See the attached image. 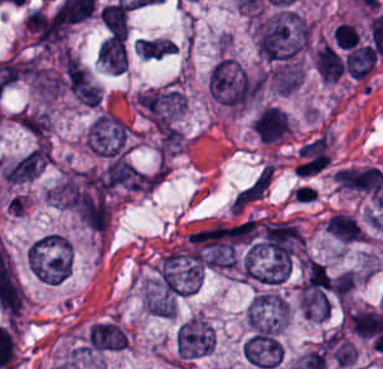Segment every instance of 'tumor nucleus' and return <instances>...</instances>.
Returning a JSON list of instances; mask_svg holds the SVG:
<instances>
[{
  "instance_id": "17",
  "label": "tumor nucleus",
  "mask_w": 383,
  "mask_h": 369,
  "mask_svg": "<svg viewBox=\"0 0 383 369\" xmlns=\"http://www.w3.org/2000/svg\"><path fill=\"white\" fill-rule=\"evenodd\" d=\"M334 39L340 48L351 49L359 44L360 33L349 21H342L334 29Z\"/></svg>"
},
{
  "instance_id": "13",
  "label": "tumor nucleus",
  "mask_w": 383,
  "mask_h": 369,
  "mask_svg": "<svg viewBox=\"0 0 383 369\" xmlns=\"http://www.w3.org/2000/svg\"><path fill=\"white\" fill-rule=\"evenodd\" d=\"M315 64L323 81L335 82L345 71L343 57L332 45L325 42L317 54Z\"/></svg>"
},
{
  "instance_id": "9",
  "label": "tumor nucleus",
  "mask_w": 383,
  "mask_h": 369,
  "mask_svg": "<svg viewBox=\"0 0 383 369\" xmlns=\"http://www.w3.org/2000/svg\"><path fill=\"white\" fill-rule=\"evenodd\" d=\"M289 318L288 304L276 292L258 290L248 307L251 325H284Z\"/></svg>"
},
{
  "instance_id": "3",
  "label": "tumor nucleus",
  "mask_w": 383,
  "mask_h": 369,
  "mask_svg": "<svg viewBox=\"0 0 383 369\" xmlns=\"http://www.w3.org/2000/svg\"><path fill=\"white\" fill-rule=\"evenodd\" d=\"M27 262L33 276L42 283L61 284L71 272L70 244L61 236L46 234L31 244Z\"/></svg>"
},
{
  "instance_id": "4",
  "label": "tumor nucleus",
  "mask_w": 383,
  "mask_h": 369,
  "mask_svg": "<svg viewBox=\"0 0 383 369\" xmlns=\"http://www.w3.org/2000/svg\"><path fill=\"white\" fill-rule=\"evenodd\" d=\"M85 140L89 149L103 158L124 159L128 153V126L118 116L105 111L91 123Z\"/></svg>"
},
{
  "instance_id": "16",
  "label": "tumor nucleus",
  "mask_w": 383,
  "mask_h": 369,
  "mask_svg": "<svg viewBox=\"0 0 383 369\" xmlns=\"http://www.w3.org/2000/svg\"><path fill=\"white\" fill-rule=\"evenodd\" d=\"M328 348L339 367H346L355 362L356 350L341 333H334L328 338Z\"/></svg>"
},
{
  "instance_id": "10",
  "label": "tumor nucleus",
  "mask_w": 383,
  "mask_h": 369,
  "mask_svg": "<svg viewBox=\"0 0 383 369\" xmlns=\"http://www.w3.org/2000/svg\"><path fill=\"white\" fill-rule=\"evenodd\" d=\"M83 347L89 352H115L128 347V337L117 321L102 319L90 325Z\"/></svg>"
},
{
  "instance_id": "8",
  "label": "tumor nucleus",
  "mask_w": 383,
  "mask_h": 369,
  "mask_svg": "<svg viewBox=\"0 0 383 369\" xmlns=\"http://www.w3.org/2000/svg\"><path fill=\"white\" fill-rule=\"evenodd\" d=\"M336 184L352 193L373 198L383 191V173L378 165H345L336 170Z\"/></svg>"
},
{
  "instance_id": "2",
  "label": "tumor nucleus",
  "mask_w": 383,
  "mask_h": 369,
  "mask_svg": "<svg viewBox=\"0 0 383 369\" xmlns=\"http://www.w3.org/2000/svg\"><path fill=\"white\" fill-rule=\"evenodd\" d=\"M212 101L229 110H243L258 98L259 77L235 59L222 57L208 76Z\"/></svg>"
},
{
  "instance_id": "11",
  "label": "tumor nucleus",
  "mask_w": 383,
  "mask_h": 369,
  "mask_svg": "<svg viewBox=\"0 0 383 369\" xmlns=\"http://www.w3.org/2000/svg\"><path fill=\"white\" fill-rule=\"evenodd\" d=\"M256 132L263 142L283 139L291 130L287 112L278 105H265L254 117Z\"/></svg>"
},
{
  "instance_id": "1",
  "label": "tumor nucleus",
  "mask_w": 383,
  "mask_h": 369,
  "mask_svg": "<svg viewBox=\"0 0 383 369\" xmlns=\"http://www.w3.org/2000/svg\"><path fill=\"white\" fill-rule=\"evenodd\" d=\"M310 29L291 9H277L259 15L254 24L258 54L272 63H292L306 48Z\"/></svg>"
},
{
  "instance_id": "6",
  "label": "tumor nucleus",
  "mask_w": 383,
  "mask_h": 369,
  "mask_svg": "<svg viewBox=\"0 0 383 369\" xmlns=\"http://www.w3.org/2000/svg\"><path fill=\"white\" fill-rule=\"evenodd\" d=\"M284 350L279 332L256 330L242 345V356L257 369H271L283 360Z\"/></svg>"
},
{
  "instance_id": "14",
  "label": "tumor nucleus",
  "mask_w": 383,
  "mask_h": 369,
  "mask_svg": "<svg viewBox=\"0 0 383 369\" xmlns=\"http://www.w3.org/2000/svg\"><path fill=\"white\" fill-rule=\"evenodd\" d=\"M378 56L373 45L362 44L347 53L345 70L353 76L365 77L377 63Z\"/></svg>"
},
{
  "instance_id": "7",
  "label": "tumor nucleus",
  "mask_w": 383,
  "mask_h": 369,
  "mask_svg": "<svg viewBox=\"0 0 383 369\" xmlns=\"http://www.w3.org/2000/svg\"><path fill=\"white\" fill-rule=\"evenodd\" d=\"M215 348V334L201 318L180 324L176 334L177 357L195 359L210 355Z\"/></svg>"
},
{
  "instance_id": "15",
  "label": "tumor nucleus",
  "mask_w": 383,
  "mask_h": 369,
  "mask_svg": "<svg viewBox=\"0 0 383 369\" xmlns=\"http://www.w3.org/2000/svg\"><path fill=\"white\" fill-rule=\"evenodd\" d=\"M136 49L142 57L158 59L176 52L177 47L170 38H137Z\"/></svg>"
},
{
  "instance_id": "12",
  "label": "tumor nucleus",
  "mask_w": 383,
  "mask_h": 369,
  "mask_svg": "<svg viewBox=\"0 0 383 369\" xmlns=\"http://www.w3.org/2000/svg\"><path fill=\"white\" fill-rule=\"evenodd\" d=\"M42 171L36 146L6 160L1 168V176L9 185L24 183Z\"/></svg>"
},
{
  "instance_id": "5",
  "label": "tumor nucleus",
  "mask_w": 383,
  "mask_h": 369,
  "mask_svg": "<svg viewBox=\"0 0 383 369\" xmlns=\"http://www.w3.org/2000/svg\"><path fill=\"white\" fill-rule=\"evenodd\" d=\"M137 105L157 131H166L181 115L185 99L180 88H147L140 92Z\"/></svg>"
}]
</instances>
